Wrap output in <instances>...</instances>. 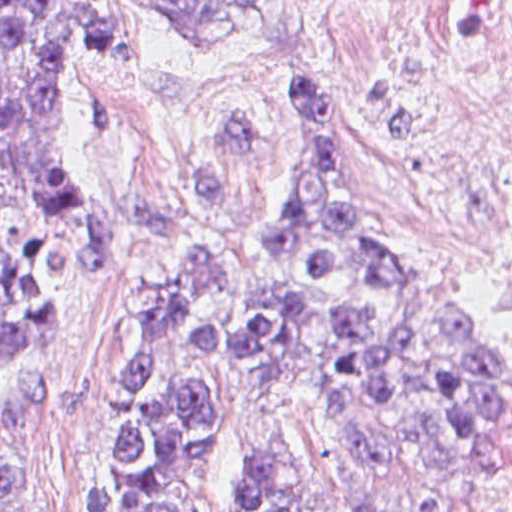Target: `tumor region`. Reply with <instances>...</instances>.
Wrapping results in <instances>:
<instances>
[{"instance_id":"tumor-region-1","label":"tumor region","mask_w":512,"mask_h":512,"mask_svg":"<svg viewBox=\"0 0 512 512\" xmlns=\"http://www.w3.org/2000/svg\"><path fill=\"white\" fill-rule=\"evenodd\" d=\"M186 36L258 48L306 0H161ZM100 0H0V363L116 266L57 95ZM102 512H512V352L393 259L296 92L248 260L201 241L134 309L90 477ZM0 512L33 466L0 445Z\"/></svg>"}]
</instances>
